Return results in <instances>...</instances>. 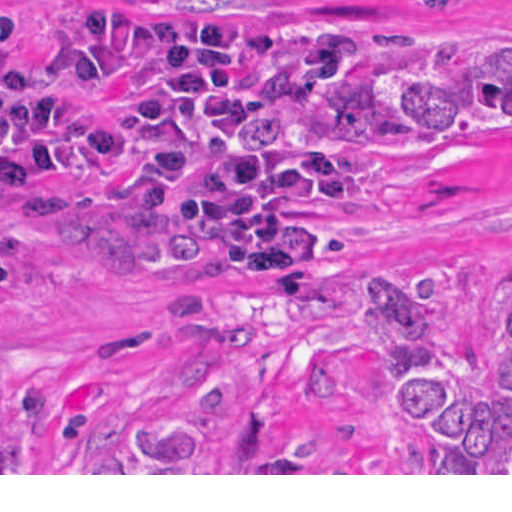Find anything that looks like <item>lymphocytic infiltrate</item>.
<instances>
[{
    "mask_svg": "<svg viewBox=\"0 0 512 512\" xmlns=\"http://www.w3.org/2000/svg\"><path fill=\"white\" fill-rule=\"evenodd\" d=\"M14 2H15V0H14ZM376 42H382V40L379 39V38L373 37L371 35H368L366 33L361 32L360 33V40H359L358 51L356 53H354L352 56H350L346 61H344L316 90H319L321 88L329 86L332 83V81L347 67V65L349 63H351L352 61H355L356 59L359 58V56L362 54V52L364 51V49L366 47H368L369 45H371L373 43H376ZM18 50H19V55H20V48H19V46H18ZM20 60H21V63H22V68H23V73H24L25 66H24L23 57H20ZM63 65H64V68L66 70L67 75H69L73 80H85V79L93 78V77H91V76H89V75L79 71L72 64V62L67 59L64 49H63ZM308 94L309 93H307L305 95H302V96H297V97H292V98H286V99L271 101V102H267V103H265L263 105H260V106H258L256 108H254L253 112L248 117L246 123L249 122L250 120H252L256 116H261V115H265V114H269V113H274V112L288 110V109L292 108L296 103H298L301 99H303ZM116 125H114V126H116ZM112 128H110V129H112ZM108 131H106V132H108ZM101 136L97 139V141H96V143H95V145L93 147L94 155H95V159H96L98 167L100 169H102L104 172H107V173H109V174H111V175H113V176H115L117 178H130V179H133L130 176H128L127 174H125L124 172H120L117 169L111 167L109 165V163L106 161V159L103 157V155L101 154ZM362 159H363V161L365 162L366 166L368 167V169L370 171L372 167L369 164L368 160H366L364 158H362ZM74 177H75V145H74L73 135H72V180H71L70 185L68 187V190H67V193H66V196L64 198L62 206H45V205H42V206H45V207H33V208L34 209H41V210H48V211H55V212H58V211L55 210V209H52V208H67L69 193H70V189H71L72 181H73ZM2 183H3V181L0 180V185ZM138 183L143 187L144 192H145L146 196L148 197V199L151 201V203L153 205L159 207L158 204L153 199V197L151 196V194L149 193V191L147 190V188L145 187V185L140 183V182H138ZM355 189H353V190H351V191H349L347 193L354 192ZM157 218H158V221H159L160 224L166 225V226H170V227H174L173 224L171 223V221L169 220V218L166 216V214L162 210L158 214ZM242 274H243V278L245 280H248V281H251V282H256L253 279H251L248 275H246L243 271H242ZM256 283L264 284L262 282H256ZM293 293H296V292H293Z\"/></svg>",
    "mask_w": 512,
    "mask_h": 512,
    "instance_id": "1",
    "label": "lymphocytic infiltrate"
}]
</instances>
